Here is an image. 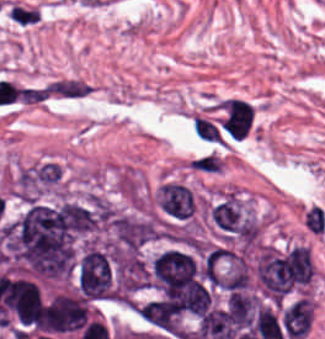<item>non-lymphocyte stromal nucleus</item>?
<instances>
[{"label":"non-lymphocyte stromal nucleus","mask_w":325,"mask_h":339,"mask_svg":"<svg viewBox=\"0 0 325 339\" xmlns=\"http://www.w3.org/2000/svg\"><path fill=\"white\" fill-rule=\"evenodd\" d=\"M193 130L199 138L221 141L222 138L214 123H212L202 113L195 112L192 116Z\"/></svg>","instance_id":"non-lymphocyte-stromal-nucleus-2"},{"label":"non-lymphocyte stromal nucleus","mask_w":325,"mask_h":339,"mask_svg":"<svg viewBox=\"0 0 325 339\" xmlns=\"http://www.w3.org/2000/svg\"><path fill=\"white\" fill-rule=\"evenodd\" d=\"M189 169L198 174L221 175L227 169L225 153L219 150H212L195 158L189 162Z\"/></svg>","instance_id":"non-lymphocyte-stromal-nucleus-1"}]
</instances>
